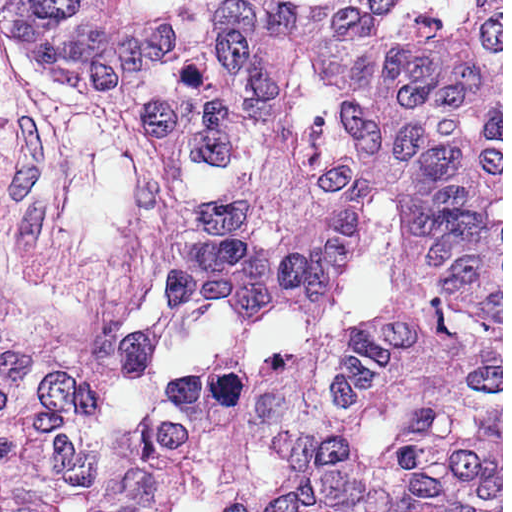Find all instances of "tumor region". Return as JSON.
I'll return each mask as SVG.
<instances>
[{
  "label": "tumor region",
  "instance_id": "e687c5a6",
  "mask_svg": "<svg viewBox=\"0 0 512 512\" xmlns=\"http://www.w3.org/2000/svg\"><path fill=\"white\" fill-rule=\"evenodd\" d=\"M0 29L217 167L256 163L234 197L167 209L161 269L191 311L332 320L383 211L402 238V285L380 323L242 375L173 379L147 438L0 512L501 293L375 0H0Z\"/></svg>",
  "mask_w": 512,
  "mask_h": 512
}]
</instances>
